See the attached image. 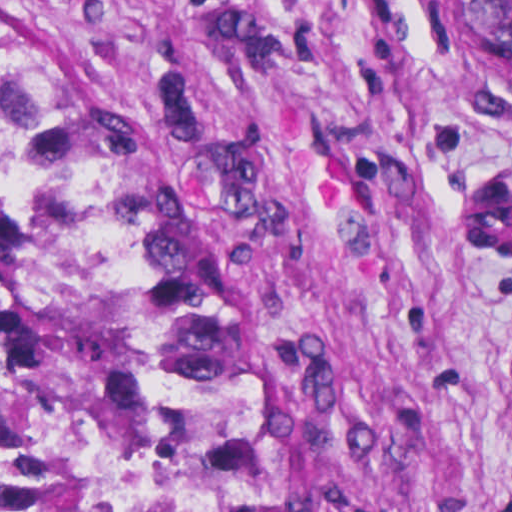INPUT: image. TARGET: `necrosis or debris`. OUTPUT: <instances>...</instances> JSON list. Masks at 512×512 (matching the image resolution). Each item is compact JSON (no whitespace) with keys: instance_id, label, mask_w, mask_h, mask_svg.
<instances>
[{"instance_id":"obj_1","label":"necrosis or debris","mask_w":512,"mask_h":512,"mask_svg":"<svg viewBox=\"0 0 512 512\" xmlns=\"http://www.w3.org/2000/svg\"><path fill=\"white\" fill-rule=\"evenodd\" d=\"M0 512H145L69 275L29 252L0 290Z\"/></svg>"}]
</instances>
